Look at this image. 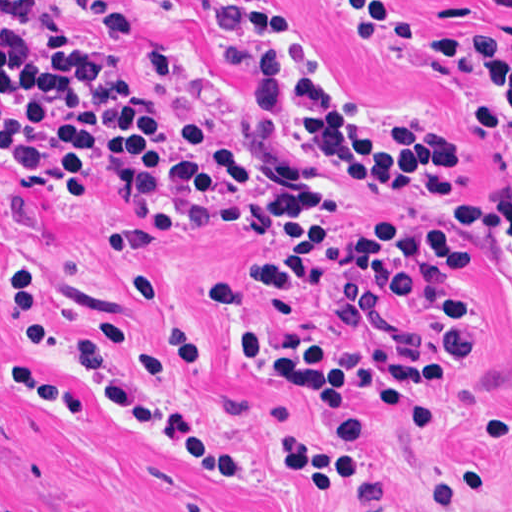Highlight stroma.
<instances>
[{
	"mask_svg": "<svg viewBox=\"0 0 512 512\" xmlns=\"http://www.w3.org/2000/svg\"><path fill=\"white\" fill-rule=\"evenodd\" d=\"M47 1L45 16L35 18L66 28L89 60L102 62L126 55L94 14L115 7L176 63L175 73L155 75L158 91L208 107L259 101L267 92L261 74L235 56L219 28L231 4L260 5L304 35L313 57L297 46L299 59L338 112L375 130L360 101L384 108L399 128L423 130L461 156L464 200L512 199V118L462 42L512 39V0ZM0 159L13 176L0 169V512H430L429 489L471 458L481 424L505 407L512 415V290L486 252L477 251L473 231L420 191L333 180L324 188L325 208L460 222L469 291L486 312V350L469 361L482 334L473 306L460 334L457 373L441 384L410 386L443 416L434 427L398 424L377 396L361 394L365 380L358 376H299L309 381L321 420L345 425L360 406L370 424L363 469L329 493L280 474L279 443L303 428L306 412L232 369L223 353L239 341L242 361L254 372L292 376L256 361L240 336L291 344L348 339L354 319L343 297L328 287L272 290L264 274L261 305L243 292L242 309L224 314L207 298V284L254 259L263 245L253 236L275 238L248 225L172 218L128 190H118L120 198L96 194L83 206L71 203L78 196L32 194ZM135 227L121 249L150 255L136 265L109 260L114 231ZM15 261L40 267L63 323L87 334L88 317L111 312L133 326L134 350L147 325L129 301L127 279L170 285L196 330L199 353L149 386L196 432L239 457L248 475L214 474L164 434L108 415L95 382L17 333L5 296ZM464 512H512V425Z\"/></svg>",
	"mask_w": 512,
	"mask_h": 512,
	"instance_id": "35a3bbf8",
	"label": "stroma"
}]
</instances>
